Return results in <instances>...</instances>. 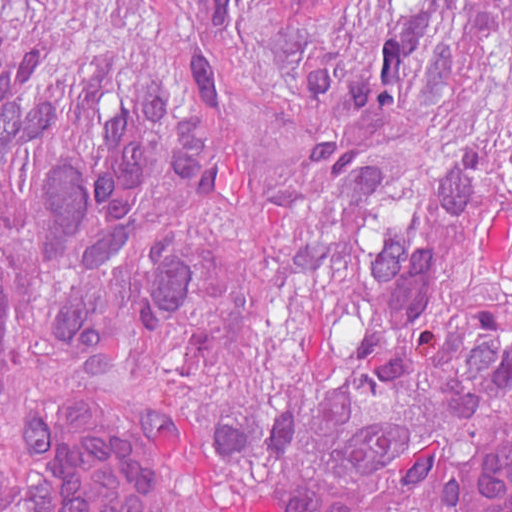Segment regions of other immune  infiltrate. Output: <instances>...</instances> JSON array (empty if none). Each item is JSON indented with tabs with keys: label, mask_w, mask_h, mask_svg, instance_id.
Returning a JSON list of instances; mask_svg holds the SVG:
<instances>
[{
	"label": "other immune infiltrate",
	"mask_w": 512,
	"mask_h": 512,
	"mask_svg": "<svg viewBox=\"0 0 512 512\" xmlns=\"http://www.w3.org/2000/svg\"><path fill=\"white\" fill-rule=\"evenodd\" d=\"M11 466L32 512H164L167 479L141 433L97 392L45 396L14 425Z\"/></svg>",
	"instance_id": "bc1004c8"
}]
</instances>
